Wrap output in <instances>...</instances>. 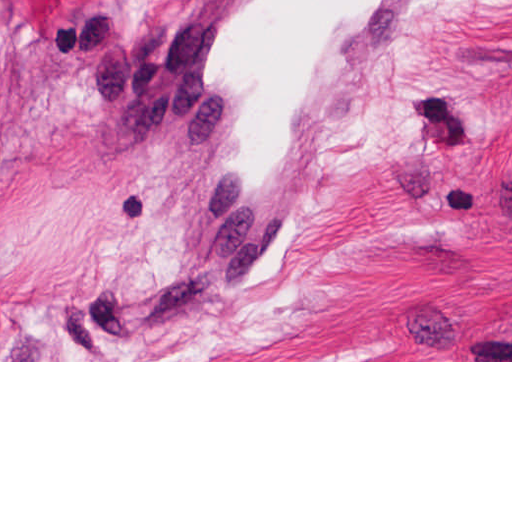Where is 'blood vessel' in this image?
Returning a JSON list of instances; mask_svg holds the SVG:
<instances>
[{"instance_id":"obj_1","label":"blood vessel","mask_w":512,"mask_h":512,"mask_svg":"<svg viewBox=\"0 0 512 512\" xmlns=\"http://www.w3.org/2000/svg\"><path fill=\"white\" fill-rule=\"evenodd\" d=\"M426 1H172L160 67L223 302H254L281 268Z\"/></svg>"}]
</instances>
